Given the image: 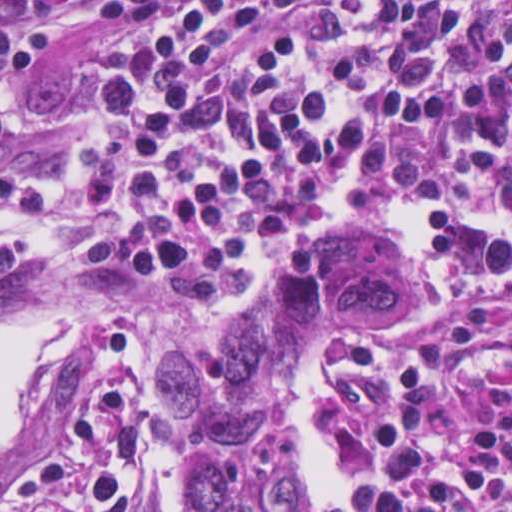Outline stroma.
<instances>
[{
  "label": "stroma",
  "mask_w": 512,
  "mask_h": 512,
  "mask_svg": "<svg viewBox=\"0 0 512 512\" xmlns=\"http://www.w3.org/2000/svg\"><path fill=\"white\" fill-rule=\"evenodd\" d=\"M103 1L0 0L17 23L44 32L47 40L37 76L0 86V108L10 134L0 144V169L27 168L57 185V202L40 210L21 234L35 267L0 296V328L19 321L78 318L77 338L55 369L34 384L27 420L0 453V492L72 426L97 379L102 335L115 324H125L138 341V411L144 423L137 511L181 512L179 468L187 463L197 437L168 416L161 403L181 345L242 331L282 262L316 237L385 240L424 276L384 236L380 217L394 197L371 191H354L341 215L326 225H301L279 235L247 264L229 296L207 309L196 308L181 294L147 289L119 276L106 228L86 202L78 173L81 158L100 134L92 96L119 76L128 60L118 41L97 22L95 10ZM419 197L436 202V209H454L512 242V220L498 193L470 189ZM484 296L481 288L455 278L453 299ZM384 404L346 414L332 402L335 413L327 430L349 472L344 490L363 488L373 469V434ZM281 432L296 452L284 427ZM307 508L315 507L303 505L302 475L301 512Z\"/></svg>",
  "instance_id": "obj_1"
}]
</instances>
